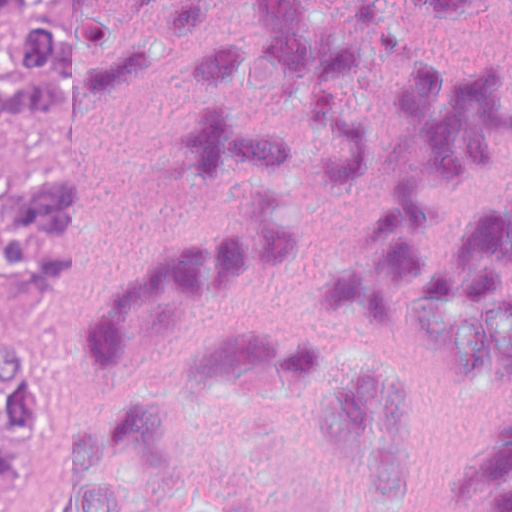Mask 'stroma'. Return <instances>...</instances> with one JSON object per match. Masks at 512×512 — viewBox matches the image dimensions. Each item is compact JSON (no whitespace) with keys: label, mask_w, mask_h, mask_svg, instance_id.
Listing matches in <instances>:
<instances>
[{"label":"stroma","mask_w":512,"mask_h":512,"mask_svg":"<svg viewBox=\"0 0 512 512\" xmlns=\"http://www.w3.org/2000/svg\"><path fill=\"white\" fill-rule=\"evenodd\" d=\"M37 0H20L0 18V36L31 10ZM79 259V239L74 261L62 284L43 293H17L0 270V336L25 343L44 380L48 399V424L42 438L18 473L2 512H18L43 459L57 370L49 367L52 351L65 328L74 296Z\"/></svg>","instance_id":"obj_1"}]
</instances>
